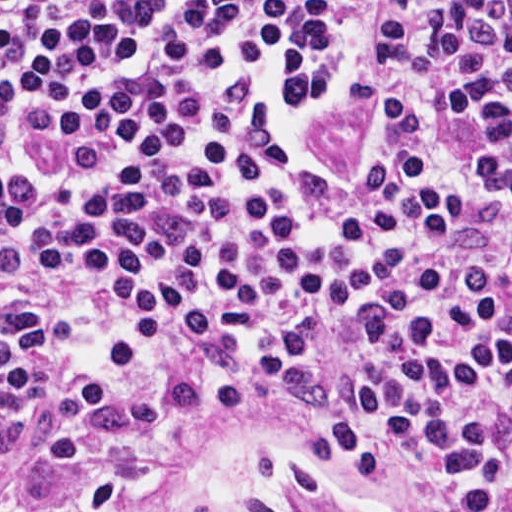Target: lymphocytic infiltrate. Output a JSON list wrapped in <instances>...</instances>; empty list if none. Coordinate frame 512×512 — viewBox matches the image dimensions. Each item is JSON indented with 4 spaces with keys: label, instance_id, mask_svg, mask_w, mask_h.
<instances>
[{
    "label": "lymphocytic infiltrate",
    "instance_id": "obj_1",
    "mask_svg": "<svg viewBox=\"0 0 512 512\" xmlns=\"http://www.w3.org/2000/svg\"><path fill=\"white\" fill-rule=\"evenodd\" d=\"M503 173L512 0H0V432L31 488L105 508L222 402L349 456L363 512H512Z\"/></svg>",
    "mask_w": 512,
    "mask_h": 512
}]
</instances>
